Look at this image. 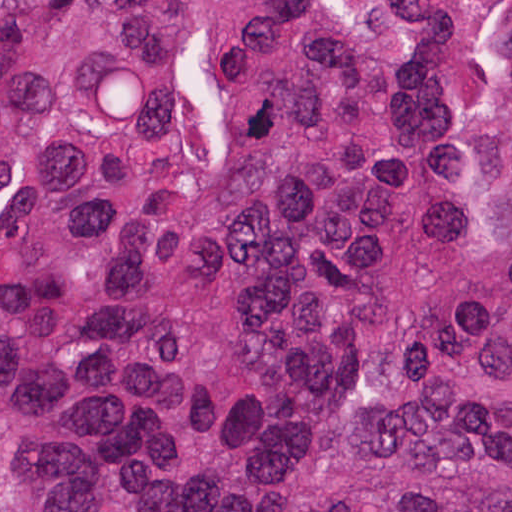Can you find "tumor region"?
I'll return each instance as SVG.
<instances>
[{
    "label": "tumor region",
    "instance_id": "1",
    "mask_svg": "<svg viewBox=\"0 0 512 512\" xmlns=\"http://www.w3.org/2000/svg\"><path fill=\"white\" fill-rule=\"evenodd\" d=\"M0 512H512V0H0Z\"/></svg>",
    "mask_w": 512,
    "mask_h": 512
}]
</instances>
